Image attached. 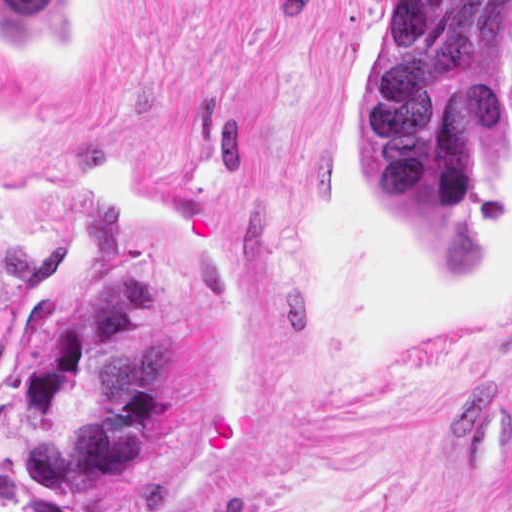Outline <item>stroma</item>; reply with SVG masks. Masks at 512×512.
Returning <instances> with one entry per match:
<instances>
[{
	"instance_id": "obj_1",
	"label": "stroma",
	"mask_w": 512,
	"mask_h": 512,
	"mask_svg": "<svg viewBox=\"0 0 512 512\" xmlns=\"http://www.w3.org/2000/svg\"><path fill=\"white\" fill-rule=\"evenodd\" d=\"M0 1H82L67 60L0 39V512H512V0ZM378 1H491L472 273L365 175ZM136 251L170 395L125 472L53 498L19 378Z\"/></svg>"
}]
</instances>
